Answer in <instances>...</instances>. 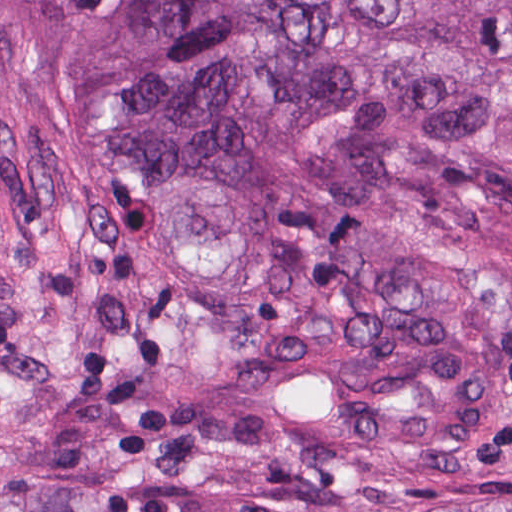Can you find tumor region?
Returning <instances> with one entry per match:
<instances>
[{
    "label": "tumor region",
    "instance_id": "e687c5a6",
    "mask_svg": "<svg viewBox=\"0 0 512 512\" xmlns=\"http://www.w3.org/2000/svg\"><path fill=\"white\" fill-rule=\"evenodd\" d=\"M1 69L116 134L191 413L512 479V304L427 237L512 187V0H1Z\"/></svg>",
    "mask_w": 512,
    "mask_h": 512
}]
</instances>
